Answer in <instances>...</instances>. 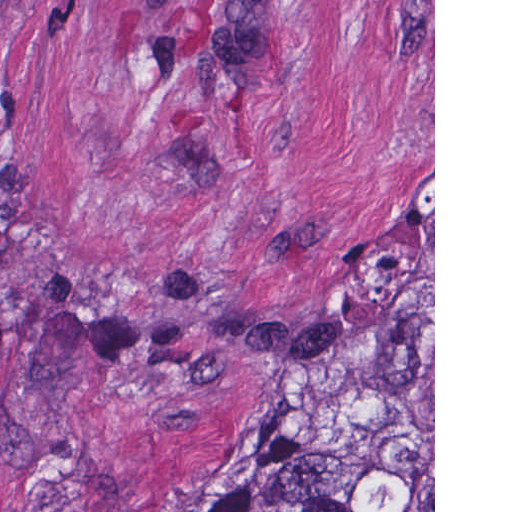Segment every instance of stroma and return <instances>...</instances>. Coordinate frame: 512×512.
Returning a JSON list of instances; mask_svg holds the SVG:
<instances>
[{
  "label": "stroma",
  "mask_w": 512,
  "mask_h": 512,
  "mask_svg": "<svg viewBox=\"0 0 512 512\" xmlns=\"http://www.w3.org/2000/svg\"><path fill=\"white\" fill-rule=\"evenodd\" d=\"M394 305L435 512V0H0V512L236 499Z\"/></svg>",
  "instance_id": "1"
}]
</instances>
